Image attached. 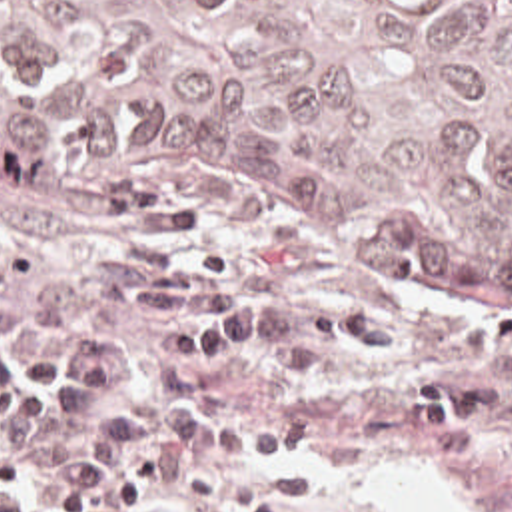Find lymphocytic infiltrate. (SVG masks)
<instances>
[{"label":"lymphocytic infiltrate","instance_id":"1","mask_svg":"<svg viewBox=\"0 0 512 512\" xmlns=\"http://www.w3.org/2000/svg\"><path fill=\"white\" fill-rule=\"evenodd\" d=\"M230 283L224 261L130 245L46 287L28 331H0V481L48 512H290L318 495V469L228 463L286 455L308 425L198 413V377L274 333Z\"/></svg>","mask_w":512,"mask_h":512}]
</instances>
